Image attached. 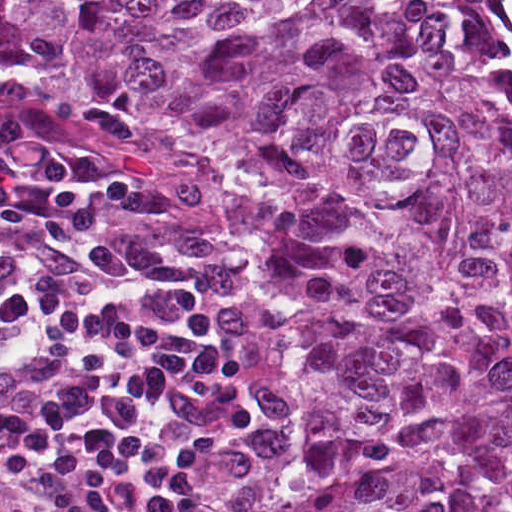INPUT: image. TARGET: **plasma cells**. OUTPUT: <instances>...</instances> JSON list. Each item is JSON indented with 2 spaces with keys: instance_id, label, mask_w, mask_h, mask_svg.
Segmentation results:
<instances>
[{
  "instance_id": "9512152a",
  "label": "plasma cells",
  "mask_w": 512,
  "mask_h": 512,
  "mask_svg": "<svg viewBox=\"0 0 512 512\" xmlns=\"http://www.w3.org/2000/svg\"><path fill=\"white\" fill-rule=\"evenodd\" d=\"M0 109V512H245L267 346L226 263L143 260L125 181L51 162Z\"/></svg>"
}]
</instances>
